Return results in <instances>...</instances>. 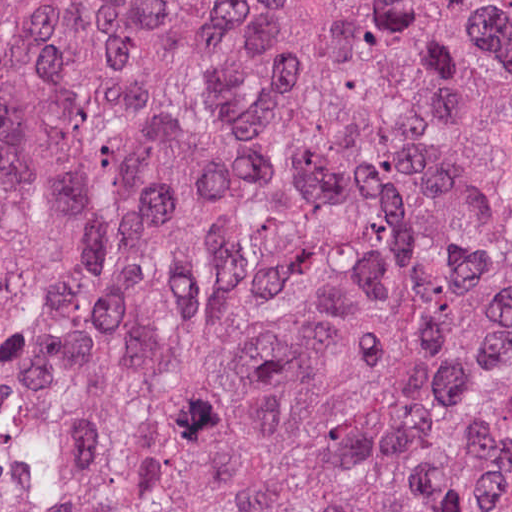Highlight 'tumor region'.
<instances>
[{
	"label": "tumor region",
	"mask_w": 512,
	"mask_h": 512,
	"mask_svg": "<svg viewBox=\"0 0 512 512\" xmlns=\"http://www.w3.org/2000/svg\"><path fill=\"white\" fill-rule=\"evenodd\" d=\"M511 215L512 0H0V512H512Z\"/></svg>",
	"instance_id": "1"
}]
</instances>
